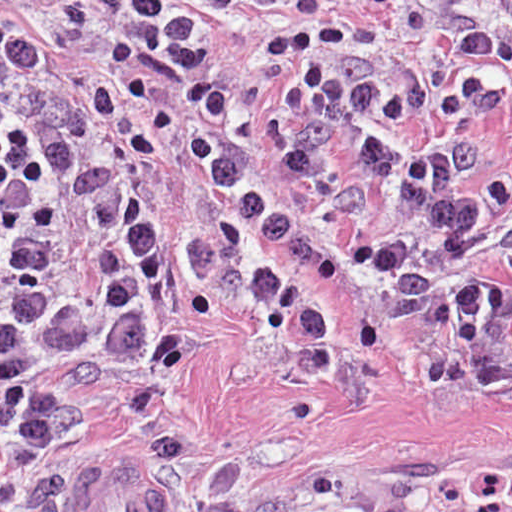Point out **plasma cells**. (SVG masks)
I'll list each match as a JSON object with an SVG mask.
<instances>
[{
  "instance_id": "obj_1",
  "label": "plasma cells",
  "mask_w": 512,
  "mask_h": 512,
  "mask_svg": "<svg viewBox=\"0 0 512 512\" xmlns=\"http://www.w3.org/2000/svg\"><path fill=\"white\" fill-rule=\"evenodd\" d=\"M74 23L121 15L118 74L93 87L103 118L133 107L153 132L117 184L79 143L59 72L0 73V470L68 467L74 434L116 411L103 364L137 340L177 271L254 275L328 299L349 281L512 374V286L480 283L488 245L465 194L479 161L443 142L401 153L405 123L464 105L480 73L389 58L338 28L268 41L293 70L270 94L216 96L214 46L177 0H63ZM189 106L179 115L151 80ZM68 512H417L297 502H81Z\"/></svg>"
}]
</instances>
